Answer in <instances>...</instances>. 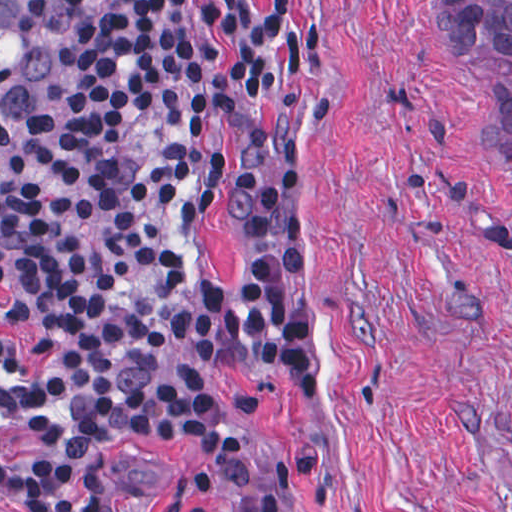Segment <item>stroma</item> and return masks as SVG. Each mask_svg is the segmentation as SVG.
<instances>
[{
	"label": "stroma",
	"mask_w": 512,
	"mask_h": 512,
	"mask_svg": "<svg viewBox=\"0 0 512 512\" xmlns=\"http://www.w3.org/2000/svg\"><path fill=\"white\" fill-rule=\"evenodd\" d=\"M440 23L441 0H319L304 17L316 76L262 128L268 163L302 179L289 309L311 340L306 406L198 363L197 283L242 249L225 210V51L211 76L214 193L156 369L201 378L292 512H512V166L490 92L512 88V69L453 63ZM65 59L66 40L53 96ZM0 328V364L35 369L37 344ZM27 428L0 417V443ZM103 465L124 512H225L204 464L170 440H123ZM0 512L23 511L0 496Z\"/></svg>",
	"instance_id": "1"
}]
</instances>
